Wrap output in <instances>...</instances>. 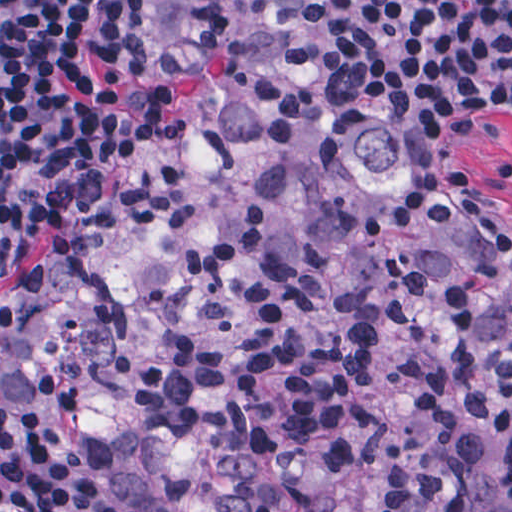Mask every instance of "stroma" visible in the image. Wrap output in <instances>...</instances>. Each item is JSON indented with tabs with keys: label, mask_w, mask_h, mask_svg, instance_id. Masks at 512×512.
Listing matches in <instances>:
<instances>
[{
	"label": "stroma",
	"mask_w": 512,
	"mask_h": 512,
	"mask_svg": "<svg viewBox=\"0 0 512 512\" xmlns=\"http://www.w3.org/2000/svg\"><path fill=\"white\" fill-rule=\"evenodd\" d=\"M339 4L361 47L405 95L427 167L448 181L478 226L512 239V66L458 70L397 42L376 21L369 0H339ZM163 110L161 89L121 156L111 189L126 165L157 137Z\"/></svg>",
	"instance_id": "stroma-1"
}]
</instances>
